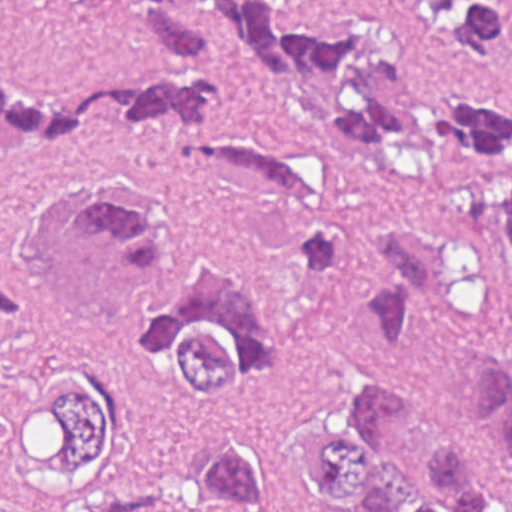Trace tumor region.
I'll return each instance as SVG.
<instances>
[{"mask_svg":"<svg viewBox=\"0 0 512 512\" xmlns=\"http://www.w3.org/2000/svg\"><path fill=\"white\" fill-rule=\"evenodd\" d=\"M122 1L138 39L184 80L144 73L46 96L0 73V151L67 147L101 104L171 123L200 182L302 210L297 272L316 282L353 254L337 186L229 118L223 54L326 97L341 151L420 185L439 215L377 229L367 344L390 352L418 314L456 305L479 335L475 409L381 374L295 434L178 443L152 400L260 396L283 338L234 251L111 178L124 166L27 216L20 248L33 272L0 276V443L16 473L62 512H284L309 495L338 512H512V108L421 54L387 0ZM393 1L512 64V27L478 0Z\"/></svg>","mask_w":512,"mask_h":512,"instance_id":"1","label":"tumor region"}]
</instances>
